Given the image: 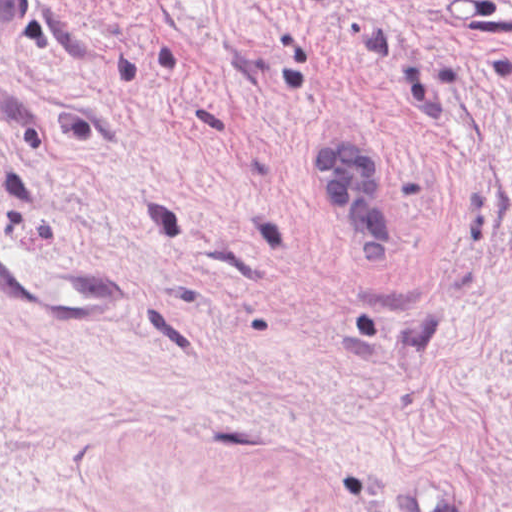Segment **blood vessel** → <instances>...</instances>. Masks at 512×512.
<instances>
[{"label": "blood vessel", "instance_id": "8fb6f2fc", "mask_svg": "<svg viewBox=\"0 0 512 512\" xmlns=\"http://www.w3.org/2000/svg\"><path fill=\"white\" fill-rule=\"evenodd\" d=\"M35 0H0V55L27 41ZM0 242V289L7 303L59 322L135 318V286L108 260Z\"/></svg>", "mask_w": 512, "mask_h": 512}]
</instances>
